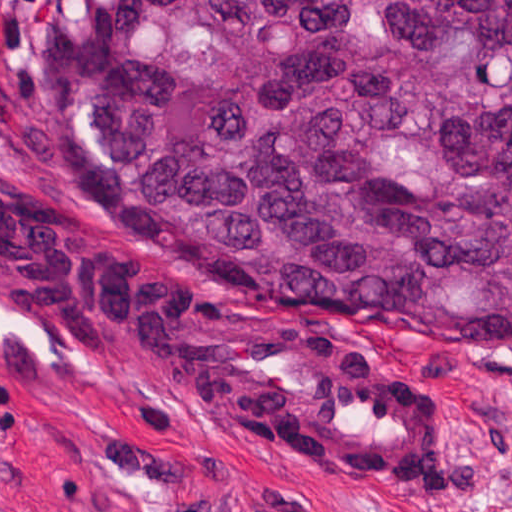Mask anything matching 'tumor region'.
Masks as SVG:
<instances>
[{"label": "tumor region", "mask_w": 512, "mask_h": 512, "mask_svg": "<svg viewBox=\"0 0 512 512\" xmlns=\"http://www.w3.org/2000/svg\"><path fill=\"white\" fill-rule=\"evenodd\" d=\"M51 68L119 210L89 213L267 302L512 353V0H57Z\"/></svg>", "instance_id": "obj_1"}]
</instances>
